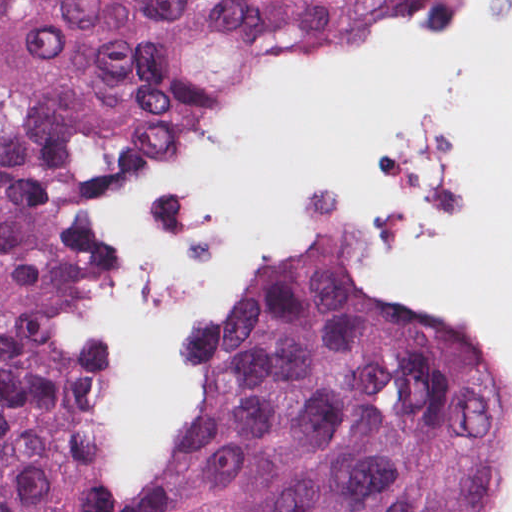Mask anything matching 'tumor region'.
Instances as JSON below:
<instances>
[{
	"instance_id": "obj_1",
	"label": "tumor region",
	"mask_w": 512,
	"mask_h": 512,
	"mask_svg": "<svg viewBox=\"0 0 512 512\" xmlns=\"http://www.w3.org/2000/svg\"><path fill=\"white\" fill-rule=\"evenodd\" d=\"M422 0H0V512H110V362L63 253L82 206L405 31ZM508 375L311 255L165 397L135 512H474Z\"/></svg>"
}]
</instances>
